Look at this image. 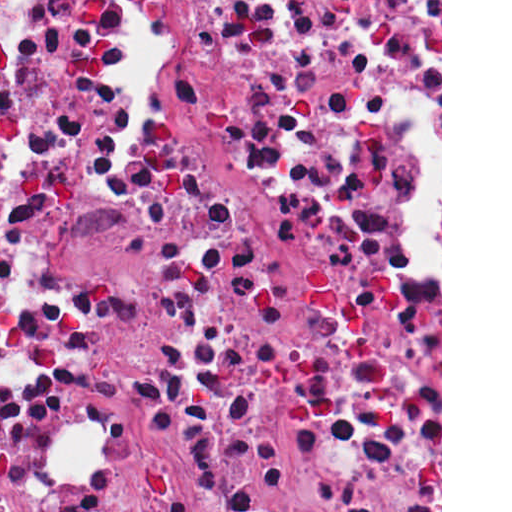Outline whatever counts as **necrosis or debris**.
I'll list each match as a JSON object with an SVG mask.
<instances>
[{
	"mask_svg": "<svg viewBox=\"0 0 512 512\" xmlns=\"http://www.w3.org/2000/svg\"><path fill=\"white\" fill-rule=\"evenodd\" d=\"M439 394L268 0H0V512H175Z\"/></svg>",
	"mask_w": 512,
	"mask_h": 512,
	"instance_id": "4bbe7bcc",
	"label": "necrosis or debris"
}]
</instances>
